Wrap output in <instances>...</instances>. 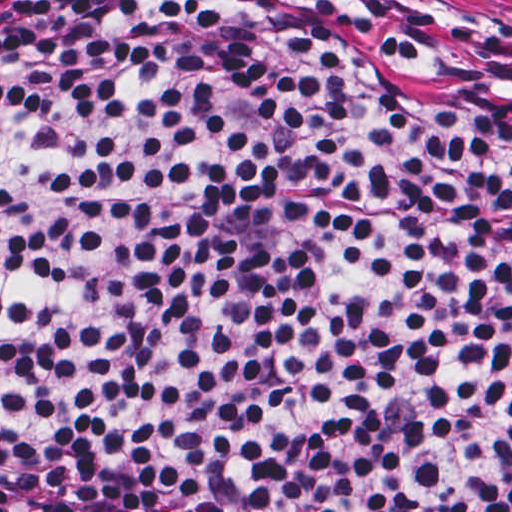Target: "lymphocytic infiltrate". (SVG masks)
I'll return each mask as SVG.
<instances>
[{
	"instance_id": "lymphocytic-infiltrate-1",
	"label": "lymphocytic infiltrate",
	"mask_w": 512,
	"mask_h": 512,
	"mask_svg": "<svg viewBox=\"0 0 512 512\" xmlns=\"http://www.w3.org/2000/svg\"><path fill=\"white\" fill-rule=\"evenodd\" d=\"M0 495L512 512V21L0 0Z\"/></svg>"
}]
</instances>
